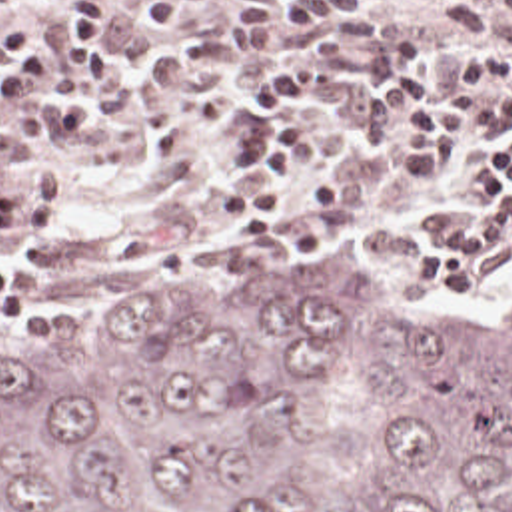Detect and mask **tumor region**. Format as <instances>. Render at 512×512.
<instances>
[{"label":"tumor region","instance_id":"e687c5a6","mask_svg":"<svg viewBox=\"0 0 512 512\" xmlns=\"http://www.w3.org/2000/svg\"><path fill=\"white\" fill-rule=\"evenodd\" d=\"M0 512H512V304L283 246L161 328L11 332Z\"/></svg>","mask_w":512,"mask_h":512}]
</instances>
